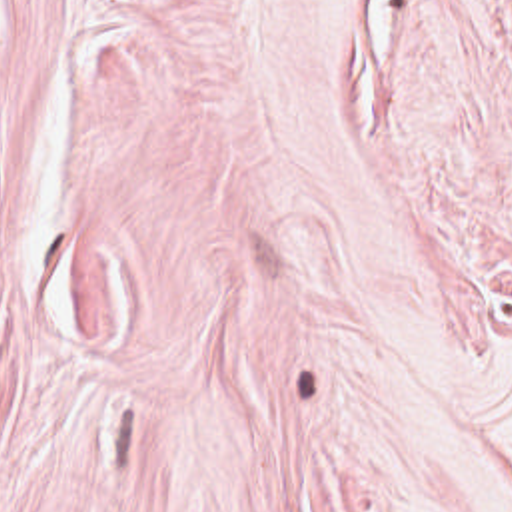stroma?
<instances>
[{"instance_id": "stroma-1", "label": "stroma", "mask_w": 512, "mask_h": 512, "mask_svg": "<svg viewBox=\"0 0 512 512\" xmlns=\"http://www.w3.org/2000/svg\"><path fill=\"white\" fill-rule=\"evenodd\" d=\"M0 512H512V0H0Z\"/></svg>"}]
</instances>
